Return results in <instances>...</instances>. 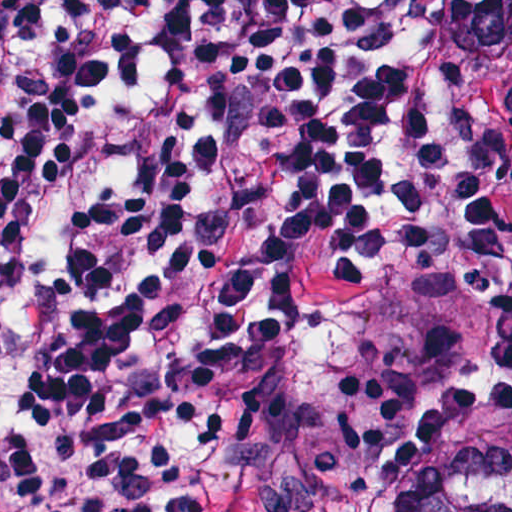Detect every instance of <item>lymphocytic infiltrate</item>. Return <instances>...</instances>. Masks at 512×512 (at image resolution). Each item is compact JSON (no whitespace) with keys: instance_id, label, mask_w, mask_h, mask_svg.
Returning a JSON list of instances; mask_svg holds the SVG:
<instances>
[{"instance_id":"lymphocytic-infiltrate-1","label":"lymphocytic infiltrate","mask_w":512,"mask_h":512,"mask_svg":"<svg viewBox=\"0 0 512 512\" xmlns=\"http://www.w3.org/2000/svg\"><path fill=\"white\" fill-rule=\"evenodd\" d=\"M427 0H0V512H219L209 379L290 382L293 286L454 293L507 223Z\"/></svg>"}]
</instances>
